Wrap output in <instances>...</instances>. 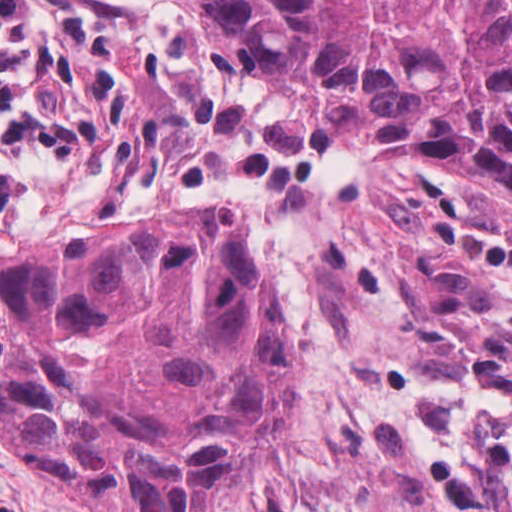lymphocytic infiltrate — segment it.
I'll return each instance as SVG.
<instances>
[{
  "label": "lymphocytic infiltrate",
  "mask_w": 512,
  "mask_h": 512,
  "mask_svg": "<svg viewBox=\"0 0 512 512\" xmlns=\"http://www.w3.org/2000/svg\"><path fill=\"white\" fill-rule=\"evenodd\" d=\"M50 33L33 0H0V213L35 192L38 173L81 150V136L37 93V61ZM260 512H286L269 502Z\"/></svg>",
  "instance_id": "1"
}]
</instances>
